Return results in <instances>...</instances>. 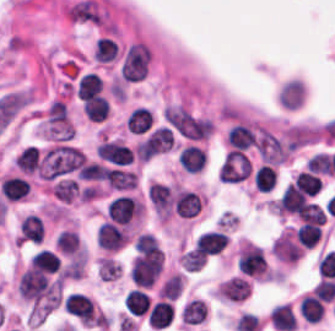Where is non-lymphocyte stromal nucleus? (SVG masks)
<instances>
[{"label":"non-lymphocyte stromal nucleus","instance_id":"dd21d789","mask_svg":"<svg viewBox=\"0 0 335 331\" xmlns=\"http://www.w3.org/2000/svg\"><path fill=\"white\" fill-rule=\"evenodd\" d=\"M150 53L147 45L142 41H136L128 45L119 72L125 81H140L148 70Z\"/></svg>","mask_w":335,"mask_h":331},{"label":"non-lymphocyte stromal nucleus","instance_id":"a72fc3eb","mask_svg":"<svg viewBox=\"0 0 335 331\" xmlns=\"http://www.w3.org/2000/svg\"><path fill=\"white\" fill-rule=\"evenodd\" d=\"M71 18L77 21L102 22L104 15L97 5L88 0H81L68 7Z\"/></svg>","mask_w":335,"mask_h":331}]
</instances>
